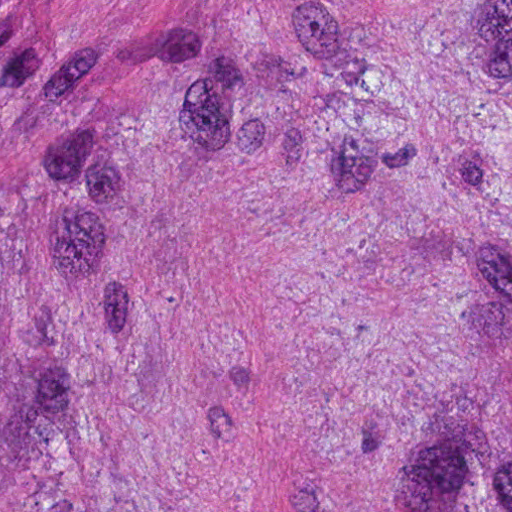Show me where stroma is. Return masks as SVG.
I'll use <instances>...</instances> for the list:
<instances>
[{
    "label": "stroma",
    "mask_w": 512,
    "mask_h": 512,
    "mask_svg": "<svg viewBox=\"0 0 512 512\" xmlns=\"http://www.w3.org/2000/svg\"><path fill=\"white\" fill-rule=\"evenodd\" d=\"M505 4L512 0H0V49L29 110H70L200 60Z\"/></svg>",
    "instance_id": "stroma-1"
}]
</instances>
